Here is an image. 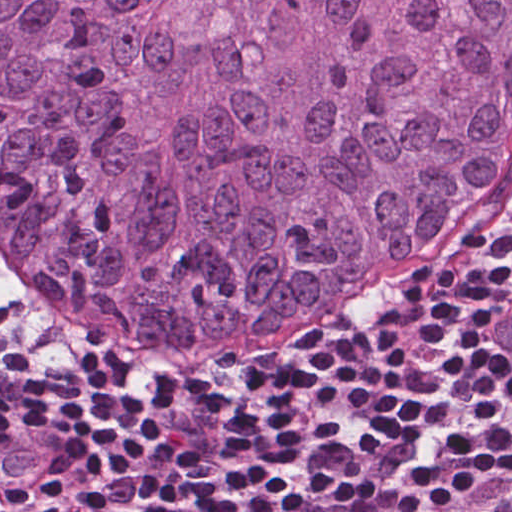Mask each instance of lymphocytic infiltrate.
<instances>
[{"label": "lymphocytic infiltrate", "mask_w": 512, "mask_h": 512, "mask_svg": "<svg viewBox=\"0 0 512 512\" xmlns=\"http://www.w3.org/2000/svg\"><path fill=\"white\" fill-rule=\"evenodd\" d=\"M74 340L0 307V512H512V149L299 324Z\"/></svg>", "instance_id": "lymphocytic-infiltrate-1"}]
</instances>
